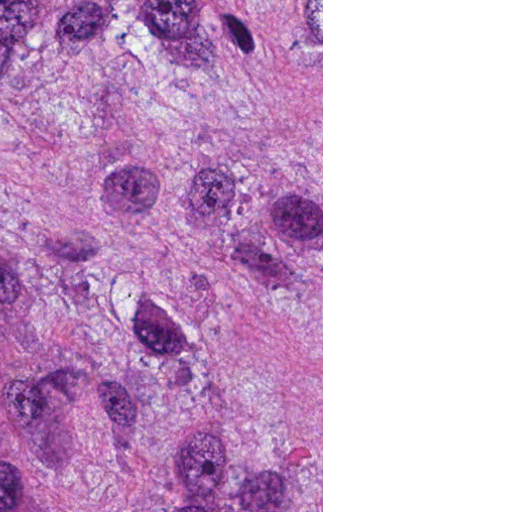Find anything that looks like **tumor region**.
<instances>
[{
    "instance_id": "1",
    "label": "tumor region",
    "mask_w": 512,
    "mask_h": 512,
    "mask_svg": "<svg viewBox=\"0 0 512 512\" xmlns=\"http://www.w3.org/2000/svg\"><path fill=\"white\" fill-rule=\"evenodd\" d=\"M0 512H161V0L0 3Z\"/></svg>"
}]
</instances>
